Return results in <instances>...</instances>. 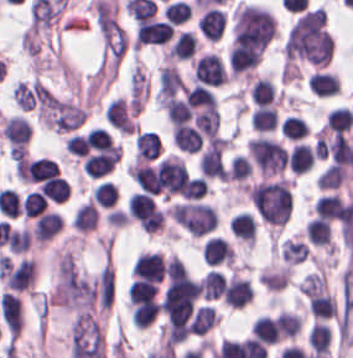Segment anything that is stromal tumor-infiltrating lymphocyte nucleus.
Segmentation results:
<instances>
[{
	"instance_id": "4245b91a",
	"label": "stromal tumor-infiltrating lymphocyte nucleus",
	"mask_w": 353,
	"mask_h": 358,
	"mask_svg": "<svg viewBox=\"0 0 353 358\" xmlns=\"http://www.w3.org/2000/svg\"><path fill=\"white\" fill-rule=\"evenodd\" d=\"M313 209L317 217L326 220H342L346 210V203L340 194L330 193L314 200Z\"/></svg>"
},
{
	"instance_id": "a6e9041d",
	"label": "stromal tumor-infiltrating lymphocyte nucleus",
	"mask_w": 353,
	"mask_h": 358,
	"mask_svg": "<svg viewBox=\"0 0 353 358\" xmlns=\"http://www.w3.org/2000/svg\"><path fill=\"white\" fill-rule=\"evenodd\" d=\"M65 149L69 151L74 156L83 157L88 151L87 141L83 134L73 133L69 134L64 143Z\"/></svg>"
},
{
	"instance_id": "2e467ee5",
	"label": "stromal tumor-infiltrating lymphocyte nucleus",
	"mask_w": 353,
	"mask_h": 358,
	"mask_svg": "<svg viewBox=\"0 0 353 358\" xmlns=\"http://www.w3.org/2000/svg\"><path fill=\"white\" fill-rule=\"evenodd\" d=\"M305 235L314 246L331 247L330 221L312 217L304 226Z\"/></svg>"
},
{
	"instance_id": "fa64b396",
	"label": "stromal tumor-infiltrating lymphocyte nucleus",
	"mask_w": 353,
	"mask_h": 358,
	"mask_svg": "<svg viewBox=\"0 0 353 358\" xmlns=\"http://www.w3.org/2000/svg\"><path fill=\"white\" fill-rule=\"evenodd\" d=\"M156 283L133 279L129 285V304L134 305L148 300L155 299Z\"/></svg>"
},
{
	"instance_id": "023d44f5",
	"label": "stromal tumor-infiltrating lymphocyte nucleus",
	"mask_w": 353,
	"mask_h": 358,
	"mask_svg": "<svg viewBox=\"0 0 353 358\" xmlns=\"http://www.w3.org/2000/svg\"><path fill=\"white\" fill-rule=\"evenodd\" d=\"M47 200L38 192L27 191L20 203V210L26 218H36L46 210Z\"/></svg>"
},
{
	"instance_id": "9e4306bb",
	"label": "stromal tumor-infiltrating lymphocyte nucleus",
	"mask_w": 353,
	"mask_h": 358,
	"mask_svg": "<svg viewBox=\"0 0 353 358\" xmlns=\"http://www.w3.org/2000/svg\"><path fill=\"white\" fill-rule=\"evenodd\" d=\"M58 165L52 159L37 157L26 159L24 163V175L26 181H41L57 175Z\"/></svg>"
},
{
	"instance_id": "84afeb40",
	"label": "stromal tumor-infiltrating lymphocyte nucleus",
	"mask_w": 353,
	"mask_h": 358,
	"mask_svg": "<svg viewBox=\"0 0 353 358\" xmlns=\"http://www.w3.org/2000/svg\"><path fill=\"white\" fill-rule=\"evenodd\" d=\"M251 175L249 158L243 154H236L229 163L227 179L243 181Z\"/></svg>"
},
{
	"instance_id": "1d375fb5",
	"label": "stromal tumor-infiltrating lymphocyte nucleus",
	"mask_w": 353,
	"mask_h": 358,
	"mask_svg": "<svg viewBox=\"0 0 353 358\" xmlns=\"http://www.w3.org/2000/svg\"><path fill=\"white\" fill-rule=\"evenodd\" d=\"M31 232L22 228L15 229L7 238V251L12 254H22L26 252L31 245Z\"/></svg>"
},
{
	"instance_id": "04cf8593",
	"label": "stromal tumor-infiltrating lymphocyte nucleus",
	"mask_w": 353,
	"mask_h": 358,
	"mask_svg": "<svg viewBox=\"0 0 353 358\" xmlns=\"http://www.w3.org/2000/svg\"><path fill=\"white\" fill-rule=\"evenodd\" d=\"M314 159L312 148L297 141L292 144L285 158L289 168L300 174L311 168Z\"/></svg>"
},
{
	"instance_id": "3c572f05",
	"label": "stromal tumor-infiltrating lymphocyte nucleus",
	"mask_w": 353,
	"mask_h": 358,
	"mask_svg": "<svg viewBox=\"0 0 353 358\" xmlns=\"http://www.w3.org/2000/svg\"><path fill=\"white\" fill-rule=\"evenodd\" d=\"M161 150L160 141L156 132L147 129H138L134 139V159H154Z\"/></svg>"
},
{
	"instance_id": "bc302bb0",
	"label": "stromal tumor-infiltrating lymphocyte nucleus",
	"mask_w": 353,
	"mask_h": 358,
	"mask_svg": "<svg viewBox=\"0 0 353 358\" xmlns=\"http://www.w3.org/2000/svg\"><path fill=\"white\" fill-rule=\"evenodd\" d=\"M226 80L228 76L224 64L212 52H205L192 62V82L195 84L218 87Z\"/></svg>"
},
{
	"instance_id": "42bb06b2",
	"label": "stromal tumor-infiltrating lymphocyte nucleus",
	"mask_w": 353,
	"mask_h": 358,
	"mask_svg": "<svg viewBox=\"0 0 353 358\" xmlns=\"http://www.w3.org/2000/svg\"><path fill=\"white\" fill-rule=\"evenodd\" d=\"M249 335L264 345H274L280 341L274 319L258 315L250 324Z\"/></svg>"
},
{
	"instance_id": "2a367800",
	"label": "stromal tumor-infiltrating lymphocyte nucleus",
	"mask_w": 353,
	"mask_h": 358,
	"mask_svg": "<svg viewBox=\"0 0 353 358\" xmlns=\"http://www.w3.org/2000/svg\"><path fill=\"white\" fill-rule=\"evenodd\" d=\"M201 256L206 264H232L234 251L223 237L210 236L203 246Z\"/></svg>"
},
{
	"instance_id": "2761f720",
	"label": "stromal tumor-infiltrating lymphocyte nucleus",
	"mask_w": 353,
	"mask_h": 358,
	"mask_svg": "<svg viewBox=\"0 0 353 358\" xmlns=\"http://www.w3.org/2000/svg\"><path fill=\"white\" fill-rule=\"evenodd\" d=\"M197 41L188 30H181L166 49L167 61L187 60L193 56Z\"/></svg>"
},
{
	"instance_id": "52c7bb5b",
	"label": "stromal tumor-infiltrating lymphocyte nucleus",
	"mask_w": 353,
	"mask_h": 358,
	"mask_svg": "<svg viewBox=\"0 0 353 358\" xmlns=\"http://www.w3.org/2000/svg\"><path fill=\"white\" fill-rule=\"evenodd\" d=\"M131 274L136 279L160 283L165 277V262L160 251H140L132 263Z\"/></svg>"
},
{
	"instance_id": "3e0999b9",
	"label": "stromal tumor-infiltrating lymphocyte nucleus",
	"mask_w": 353,
	"mask_h": 358,
	"mask_svg": "<svg viewBox=\"0 0 353 358\" xmlns=\"http://www.w3.org/2000/svg\"><path fill=\"white\" fill-rule=\"evenodd\" d=\"M217 313L212 305H198L194 312L191 335H204L216 324Z\"/></svg>"
},
{
	"instance_id": "cac63f63",
	"label": "stromal tumor-infiltrating lymphocyte nucleus",
	"mask_w": 353,
	"mask_h": 358,
	"mask_svg": "<svg viewBox=\"0 0 353 358\" xmlns=\"http://www.w3.org/2000/svg\"><path fill=\"white\" fill-rule=\"evenodd\" d=\"M248 94L253 104L269 106L274 101L275 87L268 77L257 76L250 82Z\"/></svg>"
},
{
	"instance_id": "4f13568d",
	"label": "stromal tumor-infiltrating lymphocyte nucleus",
	"mask_w": 353,
	"mask_h": 358,
	"mask_svg": "<svg viewBox=\"0 0 353 358\" xmlns=\"http://www.w3.org/2000/svg\"><path fill=\"white\" fill-rule=\"evenodd\" d=\"M62 230L61 214L47 210L33 221L31 235L37 243L51 241Z\"/></svg>"
},
{
	"instance_id": "21d57d70",
	"label": "stromal tumor-infiltrating lymphocyte nucleus",
	"mask_w": 353,
	"mask_h": 358,
	"mask_svg": "<svg viewBox=\"0 0 353 358\" xmlns=\"http://www.w3.org/2000/svg\"><path fill=\"white\" fill-rule=\"evenodd\" d=\"M280 131L286 139L295 142L306 136L309 127L300 116L288 114L281 123Z\"/></svg>"
},
{
	"instance_id": "f3e2335f",
	"label": "stromal tumor-infiltrating lymphocyte nucleus",
	"mask_w": 353,
	"mask_h": 358,
	"mask_svg": "<svg viewBox=\"0 0 353 358\" xmlns=\"http://www.w3.org/2000/svg\"><path fill=\"white\" fill-rule=\"evenodd\" d=\"M104 120L120 132H134V121L125 98H112L105 103Z\"/></svg>"
},
{
	"instance_id": "c26a33f6",
	"label": "stromal tumor-infiltrating lymphocyte nucleus",
	"mask_w": 353,
	"mask_h": 358,
	"mask_svg": "<svg viewBox=\"0 0 353 358\" xmlns=\"http://www.w3.org/2000/svg\"><path fill=\"white\" fill-rule=\"evenodd\" d=\"M250 125L258 132L275 129L278 121L275 106H255L249 116Z\"/></svg>"
},
{
	"instance_id": "abfb95fc",
	"label": "stromal tumor-infiltrating lymphocyte nucleus",
	"mask_w": 353,
	"mask_h": 358,
	"mask_svg": "<svg viewBox=\"0 0 353 358\" xmlns=\"http://www.w3.org/2000/svg\"><path fill=\"white\" fill-rule=\"evenodd\" d=\"M254 293L248 280L232 273L223 281L222 301L232 308H242L253 299Z\"/></svg>"
},
{
	"instance_id": "b6af03f8",
	"label": "stromal tumor-infiltrating lymphocyte nucleus",
	"mask_w": 353,
	"mask_h": 358,
	"mask_svg": "<svg viewBox=\"0 0 353 358\" xmlns=\"http://www.w3.org/2000/svg\"><path fill=\"white\" fill-rule=\"evenodd\" d=\"M300 325L301 317L284 309L274 319L275 332L283 340L297 335Z\"/></svg>"
},
{
	"instance_id": "18da8d3c",
	"label": "stromal tumor-infiltrating lymphocyte nucleus",
	"mask_w": 353,
	"mask_h": 358,
	"mask_svg": "<svg viewBox=\"0 0 353 358\" xmlns=\"http://www.w3.org/2000/svg\"><path fill=\"white\" fill-rule=\"evenodd\" d=\"M68 192V184L65 179L50 176L41 183V194L46 200L63 202Z\"/></svg>"
},
{
	"instance_id": "e9af9c67",
	"label": "stromal tumor-infiltrating lymphocyte nucleus",
	"mask_w": 353,
	"mask_h": 358,
	"mask_svg": "<svg viewBox=\"0 0 353 358\" xmlns=\"http://www.w3.org/2000/svg\"><path fill=\"white\" fill-rule=\"evenodd\" d=\"M228 227L236 238L253 247L256 221L248 211H241L233 216Z\"/></svg>"
},
{
	"instance_id": "6c763739",
	"label": "stromal tumor-infiltrating lymphocyte nucleus",
	"mask_w": 353,
	"mask_h": 358,
	"mask_svg": "<svg viewBox=\"0 0 353 358\" xmlns=\"http://www.w3.org/2000/svg\"><path fill=\"white\" fill-rule=\"evenodd\" d=\"M118 193L114 183L109 180H102L89 193V200L92 204L111 207L114 206Z\"/></svg>"
},
{
	"instance_id": "3290ff9b",
	"label": "stromal tumor-infiltrating lymphocyte nucleus",
	"mask_w": 353,
	"mask_h": 358,
	"mask_svg": "<svg viewBox=\"0 0 353 358\" xmlns=\"http://www.w3.org/2000/svg\"><path fill=\"white\" fill-rule=\"evenodd\" d=\"M173 33V26L155 19H141L135 25V45H161L169 41Z\"/></svg>"
},
{
	"instance_id": "8379cbfb",
	"label": "stromal tumor-infiltrating lymphocyte nucleus",
	"mask_w": 353,
	"mask_h": 358,
	"mask_svg": "<svg viewBox=\"0 0 353 358\" xmlns=\"http://www.w3.org/2000/svg\"><path fill=\"white\" fill-rule=\"evenodd\" d=\"M224 277L215 270L208 271L202 278L200 295L206 299L222 297Z\"/></svg>"
},
{
	"instance_id": "afbf053c",
	"label": "stromal tumor-infiltrating lymphocyte nucleus",
	"mask_w": 353,
	"mask_h": 358,
	"mask_svg": "<svg viewBox=\"0 0 353 358\" xmlns=\"http://www.w3.org/2000/svg\"><path fill=\"white\" fill-rule=\"evenodd\" d=\"M298 286L304 297L321 293L326 290L325 274L318 271L308 272Z\"/></svg>"
},
{
	"instance_id": "4803ca6d",
	"label": "stromal tumor-infiltrating lymphocyte nucleus",
	"mask_w": 353,
	"mask_h": 358,
	"mask_svg": "<svg viewBox=\"0 0 353 358\" xmlns=\"http://www.w3.org/2000/svg\"><path fill=\"white\" fill-rule=\"evenodd\" d=\"M310 354L314 358H328L331 349V328L319 321H314L306 334Z\"/></svg>"
},
{
	"instance_id": "9ea309e8",
	"label": "stromal tumor-infiltrating lymphocyte nucleus",
	"mask_w": 353,
	"mask_h": 358,
	"mask_svg": "<svg viewBox=\"0 0 353 358\" xmlns=\"http://www.w3.org/2000/svg\"><path fill=\"white\" fill-rule=\"evenodd\" d=\"M262 56L259 46L234 41L228 52L229 67L232 73L239 75L253 70Z\"/></svg>"
},
{
	"instance_id": "4c9ddf68",
	"label": "stromal tumor-infiltrating lymphocyte nucleus",
	"mask_w": 353,
	"mask_h": 358,
	"mask_svg": "<svg viewBox=\"0 0 353 358\" xmlns=\"http://www.w3.org/2000/svg\"><path fill=\"white\" fill-rule=\"evenodd\" d=\"M306 83L311 94L319 97H331L340 92L339 78L333 72L314 71Z\"/></svg>"
},
{
	"instance_id": "83f04bf1",
	"label": "stromal tumor-infiltrating lymphocyte nucleus",
	"mask_w": 353,
	"mask_h": 358,
	"mask_svg": "<svg viewBox=\"0 0 353 358\" xmlns=\"http://www.w3.org/2000/svg\"><path fill=\"white\" fill-rule=\"evenodd\" d=\"M165 274L169 278L187 277V268L181 258L167 257Z\"/></svg>"
},
{
	"instance_id": "a0a3295f",
	"label": "stromal tumor-infiltrating lymphocyte nucleus",
	"mask_w": 353,
	"mask_h": 358,
	"mask_svg": "<svg viewBox=\"0 0 353 358\" xmlns=\"http://www.w3.org/2000/svg\"><path fill=\"white\" fill-rule=\"evenodd\" d=\"M308 254H309V248L301 241L289 237L281 241L280 244L281 261H284L294 266L296 264L304 262Z\"/></svg>"
},
{
	"instance_id": "782c7336",
	"label": "stromal tumor-infiltrating lymphocyte nucleus",
	"mask_w": 353,
	"mask_h": 358,
	"mask_svg": "<svg viewBox=\"0 0 353 358\" xmlns=\"http://www.w3.org/2000/svg\"><path fill=\"white\" fill-rule=\"evenodd\" d=\"M160 303L154 299H148L134 303L130 307V320L134 328H144L153 322L158 314Z\"/></svg>"
},
{
	"instance_id": "02f42fee",
	"label": "stromal tumor-infiltrating lymphocyte nucleus",
	"mask_w": 353,
	"mask_h": 358,
	"mask_svg": "<svg viewBox=\"0 0 353 358\" xmlns=\"http://www.w3.org/2000/svg\"><path fill=\"white\" fill-rule=\"evenodd\" d=\"M193 123L208 137L216 133L219 125V114L217 107L210 106L197 112L193 116Z\"/></svg>"
},
{
	"instance_id": "7eef579d",
	"label": "stromal tumor-infiltrating lymphocyte nucleus",
	"mask_w": 353,
	"mask_h": 358,
	"mask_svg": "<svg viewBox=\"0 0 353 358\" xmlns=\"http://www.w3.org/2000/svg\"><path fill=\"white\" fill-rule=\"evenodd\" d=\"M308 306L313 318L317 320H325L337 314L335 298L328 293L310 294Z\"/></svg>"
},
{
	"instance_id": "16295066",
	"label": "stromal tumor-infiltrating lymphocyte nucleus",
	"mask_w": 353,
	"mask_h": 358,
	"mask_svg": "<svg viewBox=\"0 0 353 358\" xmlns=\"http://www.w3.org/2000/svg\"><path fill=\"white\" fill-rule=\"evenodd\" d=\"M335 110H337L338 112H340L341 114H343L344 116H346L347 118H349L350 120L353 121V117L351 115L350 109L348 106H335L332 107Z\"/></svg>"
}]
</instances>
